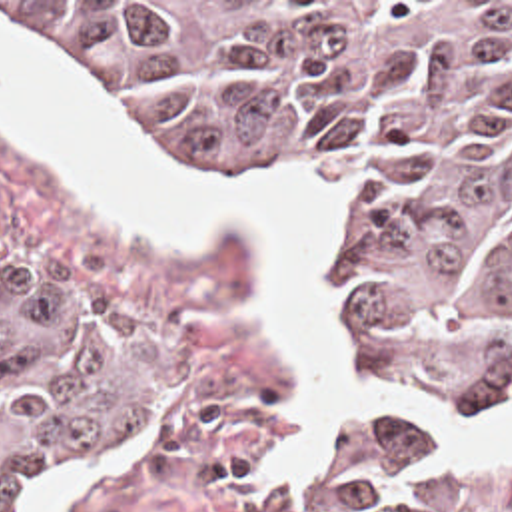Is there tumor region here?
Masks as SVG:
<instances>
[{
    "instance_id": "1",
    "label": "tumor region",
    "mask_w": 512,
    "mask_h": 512,
    "mask_svg": "<svg viewBox=\"0 0 512 512\" xmlns=\"http://www.w3.org/2000/svg\"><path fill=\"white\" fill-rule=\"evenodd\" d=\"M202 148L334 160L360 204L346 319L410 383L512 399V2H0ZM148 357L0 258V512L128 417ZM406 415L324 433L276 512H436Z\"/></svg>"
}]
</instances>
